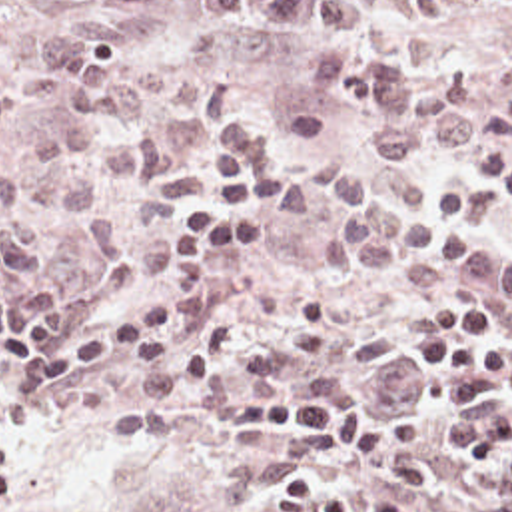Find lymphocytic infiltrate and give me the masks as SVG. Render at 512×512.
I'll list each match as a JSON object with an SVG mask.
<instances>
[{
    "label": "lymphocytic infiltrate",
    "instance_id": "1",
    "mask_svg": "<svg viewBox=\"0 0 512 512\" xmlns=\"http://www.w3.org/2000/svg\"><path fill=\"white\" fill-rule=\"evenodd\" d=\"M201 199L175 213L169 231L163 299L137 303L91 333L65 335L53 299L35 289L0 295V427L21 395L79 381L105 365H121L157 351L215 317L217 261L229 249L261 243L267 187L275 169L249 167L231 131L199 141ZM430 337L414 349L416 383L444 371L488 369L512 383V343L498 331V307L486 299L454 295L422 313ZM213 423L251 435H303L366 461L384 481L398 485L432 512H480L448 485L438 459L392 409L346 391L265 393L237 403L233 415ZM23 485V449L0 431V499ZM271 512H356L346 487L315 485L301 477L279 487ZM370 512H414L382 499Z\"/></svg>",
    "mask_w": 512,
    "mask_h": 512
}]
</instances>
